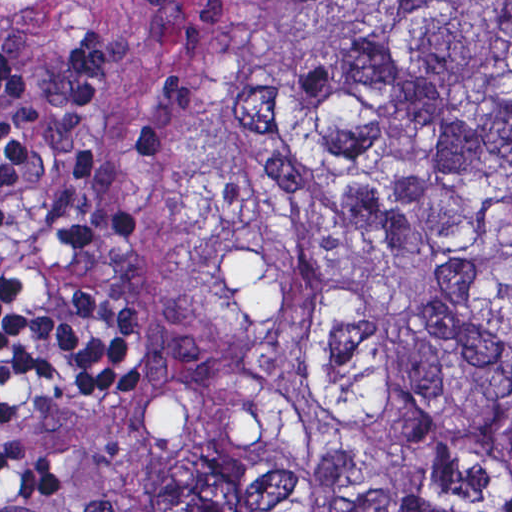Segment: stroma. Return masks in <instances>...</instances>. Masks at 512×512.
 <instances>
[{
    "mask_svg": "<svg viewBox=\"0 0 512 512\" xmlns=\"http://www.w3.org/2000/svg\"><path fill=\"white\" fill-rule=\"evenodd\" d=\"M293 1L512 0H0V67L22 119L71 147L131 234V271L151 346L113 400L11 401L16 448L60 472L58 512H127L132 439L173 392L170 244L155 226L142 115L154 87L209 43ZM512 477L455 487L434 512H509Z\"/></svg>",
    "mask_w": 512,
    "mask_h": 512,
    "instance_id": "1",
    "label": "stroma"
}]
</instances>
